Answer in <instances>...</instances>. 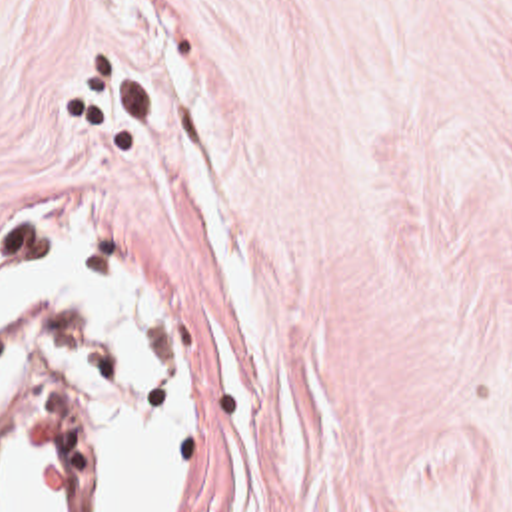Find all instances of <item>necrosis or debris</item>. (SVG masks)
Here are the masks:
<instances>
[{
    "instance_id": "4bbe7bcc",
    "label": "necrosis or debris",
    "mask_w": 512,
    "mask_h": 512,
    "mask_svg": "<svg viewBox=\"0 0 512 512\" xmlns=\"http://www.w3.org/2000/svg\"><path fill=\"white\" fill-rule=\"evenodd\" d=\"M0 365L36 381L0 411V512H76L94 443V341L40 333L0 345Z\"/></svg>"
}]
</instances>
